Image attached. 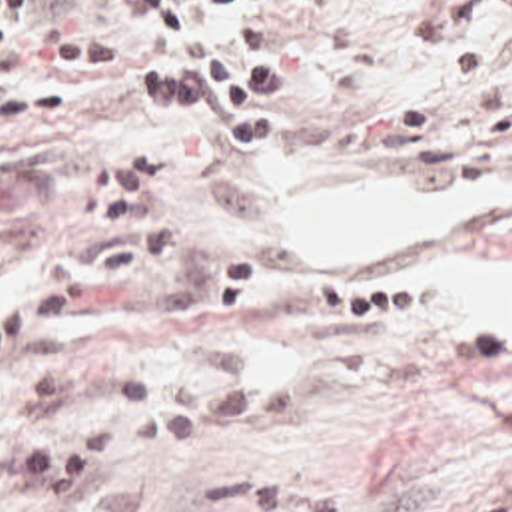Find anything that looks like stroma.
<instances>
[{"mask_svg": "<svg viewBox=\"0 0 512 512\" xmlns=\"http://www.w3.org/2000/svg\"><path fill=\"white\" fill-rule=\"evenodd\" d=\"M289 60L279 126L131 98L143 58L55 68L65 34H137L129 0H33L0 60V512L17 447L87 417L197 433L115 491L145 512H512V309L425 303L433 252L279 250L263 154L391 184L512 176V0H229ZM512 259V214L485 222Z\"/></svg>", "mask_w": 512, "mask_h": 512, "instance_id": "35a3bbf8", "label": "stroma"}]
</instances>
